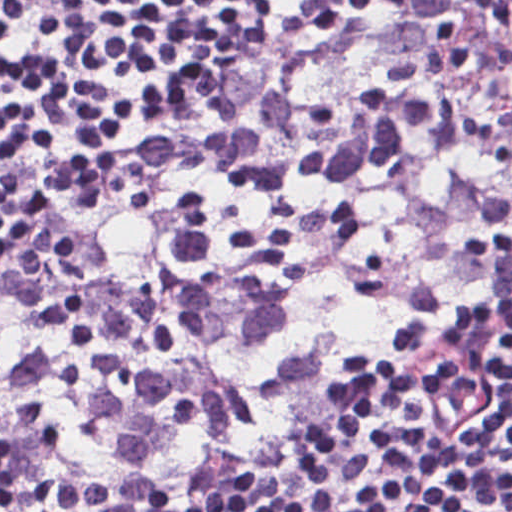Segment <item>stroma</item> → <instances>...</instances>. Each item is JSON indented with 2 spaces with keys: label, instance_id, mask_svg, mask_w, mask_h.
<instances>
[{
  "label": "stroma",
  "instance_id": "stroma-1",
  "mask_svg": "<svg viewBox=\"0 0 512 512\" xmlns=\"http://www.w3.org/2000/svg\"><path fill=\"white\" fill-rule=\"evenodd\" d=\"M303 17L282 23L267 31L232 42L193 58L168 77L158 96L137 117L120 129L98 170L127 152L155 129L181 89L202 80L274 41ZM23 243L24 241L10 250H6L0 256V269L15 255ZM396 359V357L391 359L374 371L387 367ZM271 449L251 458L209 467L186 477L164 491L150 493L126 501H102L72 512H106L129 502H154L185 493L262 459ZM463 456L464 451L449 445L428 452L398 483L377 512H432L456 475Z\"/></svg>",
  "mask_w": 512,
  "mask_h": 512
}]
</instances>
